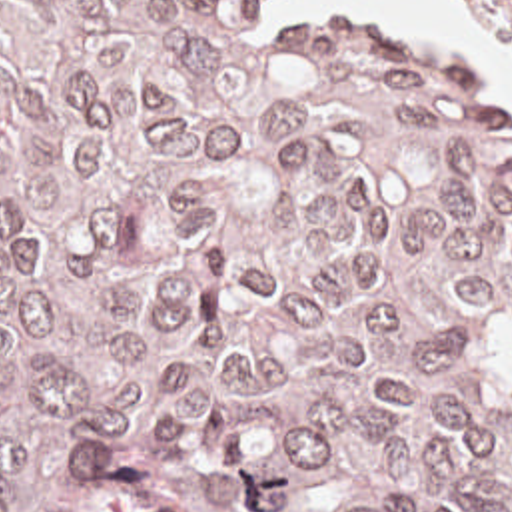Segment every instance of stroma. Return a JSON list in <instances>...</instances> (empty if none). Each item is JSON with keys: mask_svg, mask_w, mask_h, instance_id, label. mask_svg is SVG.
Returning <instances> with one entry per match:
<instances>
[{"mask_svg": "<svg viewBox=\"0 0 512 512\" xmlns=\"http://www.w3.org/2000/svg\"><path fill=\"white\" fill-rule=\"evenodd\" d=\"M466 24L500 58L512 62V48L466 4L452 0ZM262 20L308 26L326 32H366L430 52L448 72L482 90L490 106L512 120V104L466 78L446 56L418 34H402L364 12H332L320 6H290L286 0H250ZM7 512H196L182 496L154 480L121 454L93 446L55 456L21 490Z\"/></svg>", "mask_w": 512, "mask_h": 512, "instance_id": "1", "label": "stroma"}]
</instances>
